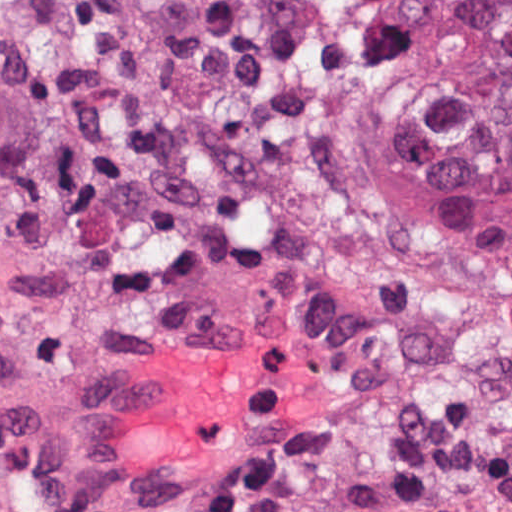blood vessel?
<instances>
[{"instance_id": "8fb6f2fc", "label": "blood vessel", "mask_w": 512, "mask_h": 512, "mask_svg": "<svg viewBox=\"0 0 512 512\" xmlns=\"http://www.w3.org/2000/svg\"><path fill=\"white\" fill-rule=\"evenodd\" d=\"M271 327L171 341L0 419V512H179L301 366Z\"/></svg>"}]
</instances>
